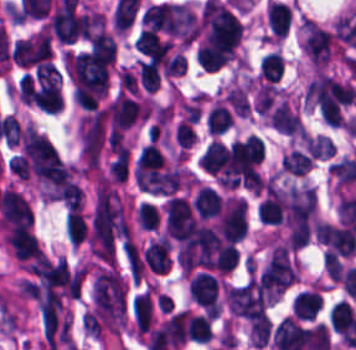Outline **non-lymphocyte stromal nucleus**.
I'll return each instance as SVG.
<instances>
[{
  "label": "non-lymphocyte stromal nucleus",
  "instance_id": "obj_1",
  "mask_svg": "<svg viewBox=\"0 0 356 350\" xmlns=\"http://www.w3.org/2000/svg\"><path fill=\"white\" fill-rule=\"evenodd\" d=\"M181 170L138 161L135 182L141 190L171 193L181 185Z\"/></svg>",
  "mask_w": 356,
  "mask_h": 350
},
{
  "label": "non-lymphocyte stromal nucleus",
  "instance_id": "obj_2",
  "mask_svg": "<svg viewBox=\"0 0 356 350\" xmlns=\"http://www.w3.org/2000/svg\"><path fill=\"white\" fill-rule=\"evenodd\" d=\"M322 305L321 293L316 289H303L294 299L295 316L301 319H313Z\"/></svg>",
  "mask_w": 356,
  "mask_h": 350
},
{
  "label": "non-lymphocyte stromal nucleus",
  "instance_id": "obj_3",
  "mask_svg": "<svg viewBox=\"0 0 356 350\" xmlns=\"http://www.w3.org/2000/svg\"><path fill=\"white\" fill-rule=\"evenodd\" d=\"M198 160L201 166L214 173L228 162V150L222 140L212 139Z\"/></svg>",
  "mask_w": 356,
  "mask_h": 350
},
{
  "label": "non-lymphocyte stromal nucleus",
  "instance_id": "obj_4",
  "mask_svg": "<svg viewBox=\"0 0 356 350\" xmlns=\"http://www.w3.org/2000/svg\"><path fill=\"white\" fill-rule=\"evenodd\" d=\"M301 138L311 157H330L335 154L336 144L323 134H302Z\"/></svg>",
  "mask_w": 356,
  "mask_h": 350
},
{
  "label": "non-lymphocyte stromal nucleus",
  "instance_id": "obj_5",
  "mask_svg": "<svg viewBox=\"0 0 356 350\" xmlns=\"http://www.w3.org/2000/svg\"><path fill=\"white\" fill-rule=\"evenodd\" d=\"M283 167L286 171L303 175L311 169V155L301 149H292L283 158Z\"/></svg>",
  "mask_w": 356,
  "mask_h": 350
},
{
  "label": "non-lymphocyte stromal nucleus",
  "instance_id": "obj_6",
  "mask_svg": "<svg viewBox=\"0 0 356 350\" xmlns=\"http://www.w3.org/2000/svg\"><path fill=\"white\" fill-rule=\"evenodd\" d=\"M137 215L144 228H157L159 224V214L156 207L148 202H141L137 210Z\"/></svg>",
  "mask_w": 356,
  "mask_h": 350
}]
</instances>
